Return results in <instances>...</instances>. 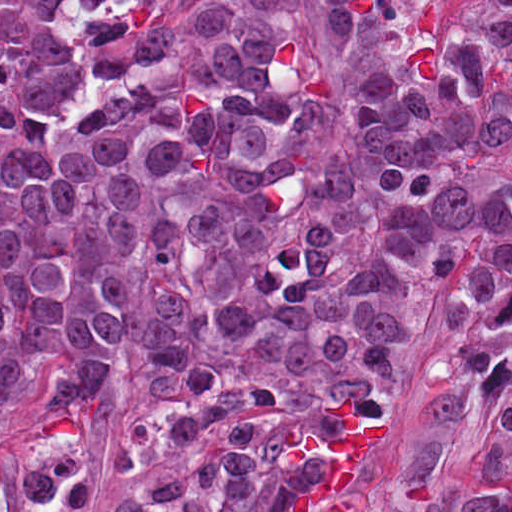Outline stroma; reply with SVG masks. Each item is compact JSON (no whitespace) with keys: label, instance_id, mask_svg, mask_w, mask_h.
I'll use <instances>...</instances> for the list:
<instances>
[{"label":"stroma","instance_id":"obj_1","mask_svg":"<svg viewBox=\"0 0 512 512\" xmlns=\"http://www.w3.org/2000/svg\"><path fill=\"white\" fill-rule=\"evenodd\" d=\"M448 284L432 292L426 332L413 351L390 406L377 494L400 492L407 458V425L424 395L427 369L442 353L437 320ZM153 388L134 354L124 353L107 365L94 394L64 414L53 415L48 409V390L33 392L0 418V458L15 463L56 438L77 437L84 452L83 467L98 495L87 512H110L109 507L127 489L154 479L170 467L164 459L143 460L127 469L118 465L128 426ZM492 440L493 427L485 417L464 422L449 441L438 476L460 492L478 493ZM1 512H21L12 488Z\"/></svg>","mask_w":512,"mask_h":512}]
</instances>
